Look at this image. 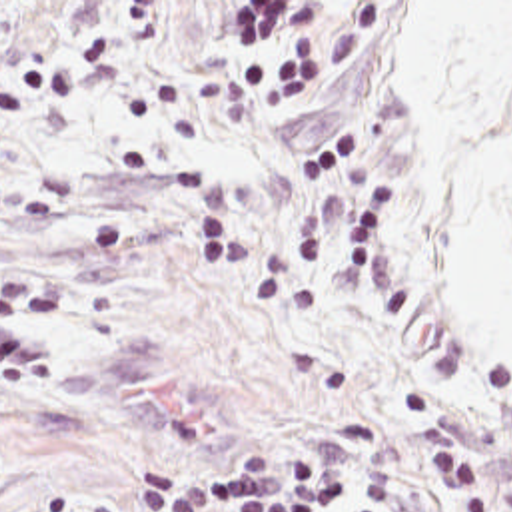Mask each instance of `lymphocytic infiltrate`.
<instances>
[{
    "instance_id": "f902f5d3",
    "label": "lymphocytic infiltrate",
    "mask_w": 512,
    "mask_h": 512,
    "mask_svg": "<svg viewBox=\"0 0 512 512\" xmlns=\"http://www.w3.org/2000/svg\"><path fill=\"white\" fill-rule=\"evenodd\" d=\"M50 371L48 299L28 275L2 270L0 377L44 381ZM344 501V467L322 445L292 457L262 447L206 477H188L174 463L154 471L134 512H334Z\"/></svg>"
}]
</instances>
